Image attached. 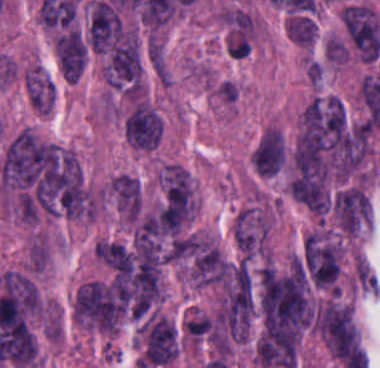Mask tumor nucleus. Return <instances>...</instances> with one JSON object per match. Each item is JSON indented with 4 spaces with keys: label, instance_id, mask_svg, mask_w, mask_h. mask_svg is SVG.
Listing matches in <instances>:
<instances>
[{
    "label": "tumor nucleus",
    "instance_id": "12",
    "mask_svg": "<svg viewBox=\"0 0 380 368\" xmlns=\"http://www.w3.org/2000/svg\"><path fill=\"white\" fill-rule=\"evenodd\" d=\"M285 163H286V145L283 138L271 177L281 172Z\"/></svg>",
    "mask_w": 380,
    "mask_h": 368
},
{
    "label": "tumor nucleus",
    "instance_id": "11",
    "mask_svg": "<svg viewBox=\"0 0 380 368\" xmlns=\"http://www.w3.org/2000/svg\"><path fill=\"white\" fill-rule=\"evenodd\" d=\"M252 47L251 30L232 28L227 39L226 48L231 58H243Z\"/></svg>",
    "mask_w": 380,
    "mask_h": 368
},
{
    "label": "tumor nucleus",
    "instance_id": "8",
    "mask_svg": "<svg viewBox=\"0 0 380 368\" xmlns=\"http://www.w3.org/2000/svg\"><path fill=\"white\" fill-rule=\"evenodd\" d=\"M27 94L37 111L50 113L54 100L53 80L41 70H28Z\"/></svg>",
    "mask_w": 380,
    "mask_h": 368
},
{
    "label": "tumor nucleus",
    "instance_id": "2",
    "mask_svg": "<svg viewBox=\"0 0 380 368\" xmlns=\"http://www.w3.org/2000/svg\"><path fill=\"white\" fill-rule=\"evenodd\" d=\"M270 227L271 221L263 211L246 208L238 214L233 233L242 263L266 257Z\"/></svg>",
    "mask_w": 380,
    "mask_h": 368
},
{
    "label": "tumor nucleus",
    "instance_id": "4",
    "mask_svg": "<svg viewBox=\"0 0 380 368\" xmlns=\"http://www.w3.org/2000/svg\"><path fill=\"white\" fill-rule=\"evenodd\" d=\"M341 19L362 60H376L380 51V24L375 12L366 5H346Z\"/></svg>",
    "mask_w": 380,
    "mask_h": 368
},
{
    "label": "tumor nucleus",
    "instance_id": "5",
    "mask_svg": "<svg viewBox=\"0 0 380 368\" xmlns=\"http://www.w3.org/2000/svg\"><path fill=\"white\" fill-rule=\"evenodd\" d=\"M123 35L122 20L112 5L92 0L89 7V44L92 50L107 52Z\"/></svg>",
    "mask_w": 380,
    "mask_h": 368
},
{
    "label": "tumor nucleus",
    "instance_id": "6",
    "mask_svg": "<svg viewBox=\"0 0 380 368\" xmlns=\"http://www.w3.org/2000/svg\"><path fill=\"white\" fill-rule=\"evenodd\" d=\"M161 129L158 110L131 108L124 115L123 134L136 149H153L158 144Z\"/></svg>",
    "mask_w": 380,
    "mask_h": 368
},
{
    "label": "tumor nucleus",
    "instance_id": "3",
    "mask_svg": "<svg viewBox=\"0 0 380 368\" xmlns=\"http://www.w3.org/2000/svg\"><path fill=\"white\" fill-rule=\"evenodd\" d=\"M302 343L299 329L261 332L255 345L256 362L263 368H293Z\"/></svg>",
    "mask_w": 380,
    "mask_h": 368
},
{
    "label": "tumor nucleus",
    "instance_id": "7",
    "mask_svg": "<svg viewBox=\"0 0 380 368\" xmlns=\"http://www.w3.org/2000/svg\"><path fill=\"white\" fill-rule=\"evenodd\" d=\"M59 69L64 78L75 82L87 64V48L77 30H69L54 40Z\"/></svg>",
    "mask_w": 380,
    "mask_h": 368
},
{
    "label": "tumor nucleus",
    "instance_id": "1",
    "mask_svg": "<svg viewBox=\"0 0 380 368\" xmlns=\"http://www.w3.org/2000/svg\"><path fill=\"white\" fill-rule=\"evenodd\" d=\"M257 309L266 329H303L315 321L311 286L298 261L266 263L258 272Z\"/></svg>",
    "mask_w": 380,
    "mask_h": 368
},
{
    "label": "tumor nucleus",
    "instance_id": "9",
    "mask_svg": "<svg viewBox=\"0 0 380 368\" xmlns=\"http://www.w3.org/2000/svg\"><path fill=\"white\" fill-rule=\"evenodd\" d=\"M94 254L122 274L127 272L133 263V253L123 243L99 239Z\"/></svg>",
    "mask_w": 380,
    "mask_h": 368
},
{
    "label": "tumor nucleus",
    "instance_id": "10",
    "mask_svg": "<svg viewBox=\"0 0 380 368\" xmlns=\"http://www.w3.org/2000/svg\"><path fill=\"white\" fill-rule=\"evenodd\" d=\"M287 35L293 43L313 45L317 36V24L304 13H291L287 20Z\"/></svg>",
    "mask_w": 380,
    "mask_h": 368
}]
</instances>
